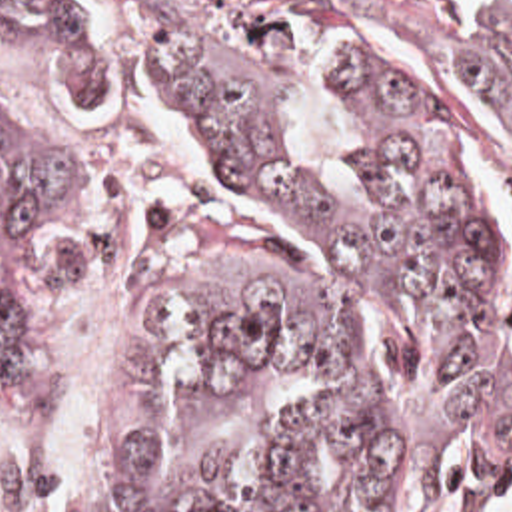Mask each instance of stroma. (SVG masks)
Returning a JSON list of instances; mask_svg holds the SVG:
<instances>
[{
	"label": "stroma",
	"instance_id": "35a3bbf8",
	"mask_svg": "<svg viewBox=\"0 0 512 512\" xmlns=\"http://www.w3.org/2000/svg\"><path fill=\"white\" fill-rule=\"evenodd\" d=\"M285 15L327 19L385 11L399 23H512V0H243Z\"/></svg>",
	"mask_w": 512,
	"mask_h": 512
}]
</instances>
